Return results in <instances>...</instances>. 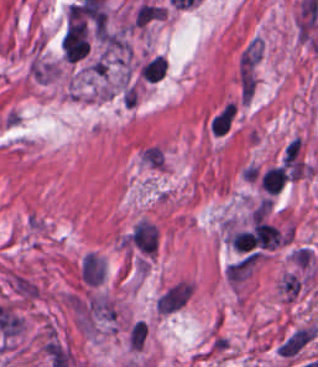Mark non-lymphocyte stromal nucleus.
<instances>
[{"label": "non-lymphocyte stromal nucleus", "mask_w": 318, "mask_h": 367, "mask_svg": "<svg viewBox=\"0 0 318 367\" xmlns=\"http://www.w3.org/2000/svg\"><path fill=\"white\" fill-rule=\"evenodd\" d=\"M147 331L146 323L136 321L130 330L131 346L133 348H141Z\"/></svg>", "instance_id": "obj_4"}, {"label": "non-lymphocyte stromal nucleus", "mask_w": 318, "mask_h": 367, "mask_svg": "<svg viewBox=\"0 0 318 367\" xmlns=\"http://www.w3.org/2000/svg\"><path fill=\"white\" fill-rule=\"evenodd\" d=\"M192 294L190 280L178 279L156 298V309L161 314L172 315L189 302Z\"/></svg>", "instance_id": "obj_1"}, {"label": "non-lymphocyte stromal nucleus", "mask_w": 318, "mask_h": 367, "mask_svg": "<svg viewBox=\"0 0 318 367\" xmlns=\"http://www.w3.org/2000/svg\"><path fill=\"white\" fill-rule=\"evenodd\" d=\"M81 274L85 281L91 284L101 283L103 268L96 254L89 253L81 263Z\"/></svg>", "instance_id": "obj_3"}, {"label": "non-lymphocyte stromal nucleus", "mask_w": 318, "mask_h": 367, "mask_svg": "<svg viewBox=\"0 0 318 367\" xmlns=\"http://www.w3.org/2000/svg\"><path fill=\"white\" fill-rule=\"evenodd\" d=\"M310 331L306 327H298L277 349V352L292 356L295 354L309 339Z\"/></svg>", "instance_id": "obj_2"}]
</instances>
